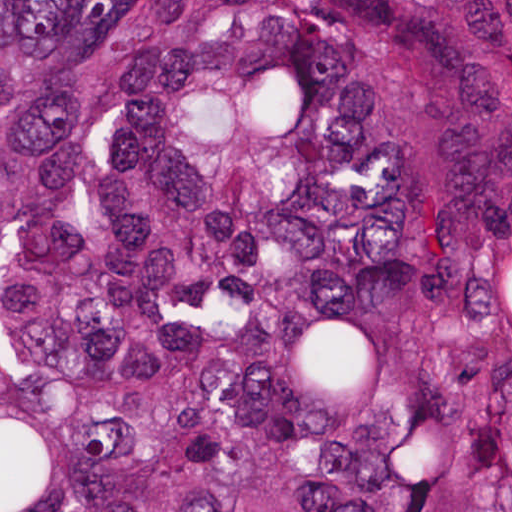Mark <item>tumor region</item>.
<instances>
[{
  "instance_id": "e687c5a6",
  "label": "tumor region",
  "mask_w": 512,
  "mask_h": 512,
  "mask_svg": "<svg viewBox=\"0 0 512 512\" xmlns=\"http://www.w3.org/2000/svg\"><path fill=\"white\" fill-rule=\"evenodd\" d=\"M0 512H512V1H0Z\"/></svg>"
}]
</instances>
